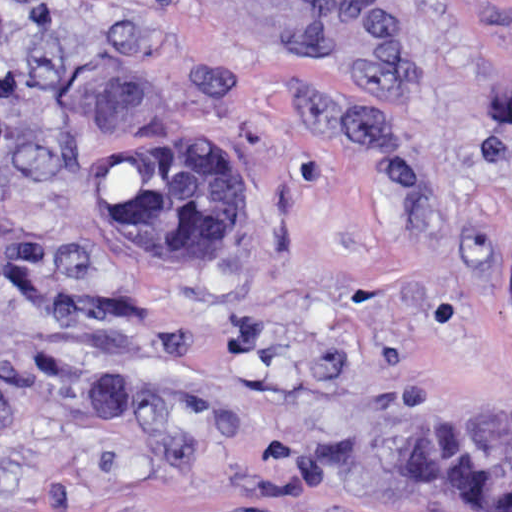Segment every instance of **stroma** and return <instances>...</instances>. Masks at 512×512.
Returning <instances> with one entry per match:
<instances>
[{
	"label": "stroma",
	"instance_id": "obj_1",
	"mask_svg": "<svg viewBox=\"0 0 512 512\" xmlns=\"http://www.w3.org/2000/svg\"><path fill=\"white\" fill-rule=\"evenodd\" d=\"M208 127L249 245L166 273L107 154ZM512 453V0H0V512H465L397 461Z\"/></svg>",
	"mask_w": 512,
	"mask_h": 512
}]
</instances>
